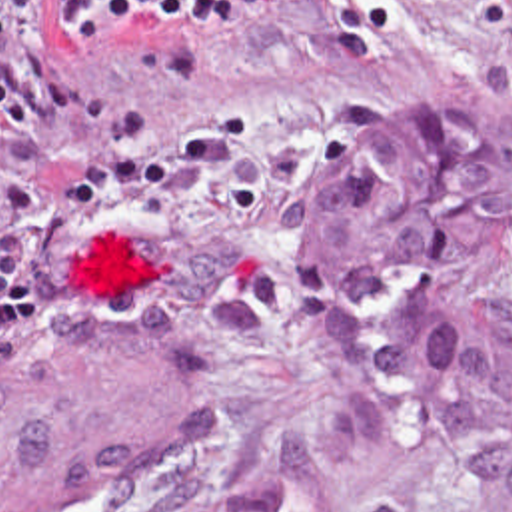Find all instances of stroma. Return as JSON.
Instances as JSON below:
<instances>
[{
	"label": "stroma",
	"instance_id": "35a3bbf8",
	"mask_svg": "<svg viewBox=\"0 0 512 512\" xmlns=\"http://www.w3.org/2000/svg\"><path fill=\"white\" fill-rule=\"evenodd\" d=\"M0 18L93 96L0 126V350L111 336L133 308L191 342L219 432L147 512L223 501L347 370L299 306V216L393 126L512 120V0H253L201 32L73 28L55 0H0ZM479 493L481 471L441 463L371 512H475Z\"/></svg>",
	"mask_w": 512,
	"mask_h": 512
}]
</instances>
